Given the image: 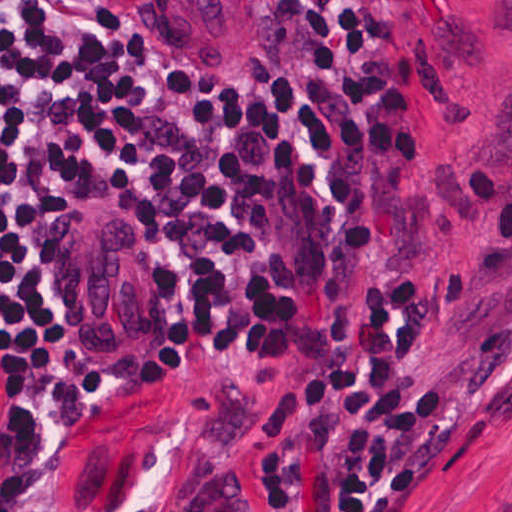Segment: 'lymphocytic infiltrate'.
Segmentation results:
<instances>
[{
	"mask_svg": "<svg viewBox=\"0 0 512 512\" xmlns=\"http://www.w3.org/2000/svg\"><path fill=\"white\" fill-rule=\"evenodd\" d=\"M393 0H269L264 89L146 73L110 117L108 187L190 273L193 369L250 401L238 474L174 512H395L460 431L458 394L415 369L512 270V175L474 168L475 251L416 289L400 175L426 158L429 70L385 36ZM113 87L96 0H0V355L17 450L106 429L91 356L33 311L41 204ZM0 512H33L4 504Z\"/></svg>",
	"mask_w": 512,
	"mask_h": 512,
	"instance_id": "obj_1",
	"label": "lymphocytic infiltrate"
}]
</instances>
